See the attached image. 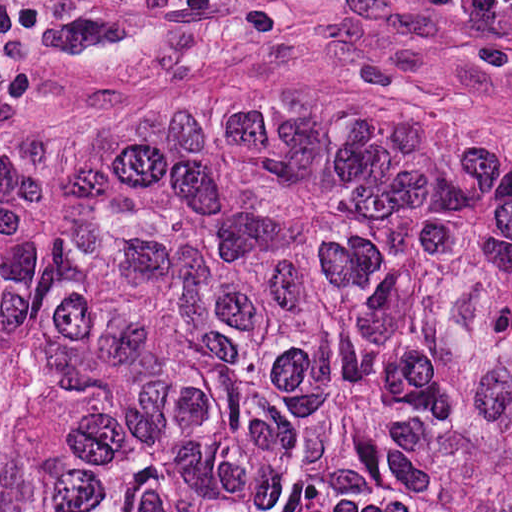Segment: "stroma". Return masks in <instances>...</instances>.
Listing matches in <instances>:
<instances>
[{
	"instance_id": "obj_1",
	"label": "stroma",
	"mask_w": 512,
	"mask_h": 512,
	"mask_svg": "<svg viewBox=\"0 0 512 512\" xmlns=\"http://www.w3.org/2000/svg\"><path fill=\"white\" fill-rule=\"evenodd\" d=\"M186 95L512 132V0H0V135Z\"/></svg>"
}]
</instances>
